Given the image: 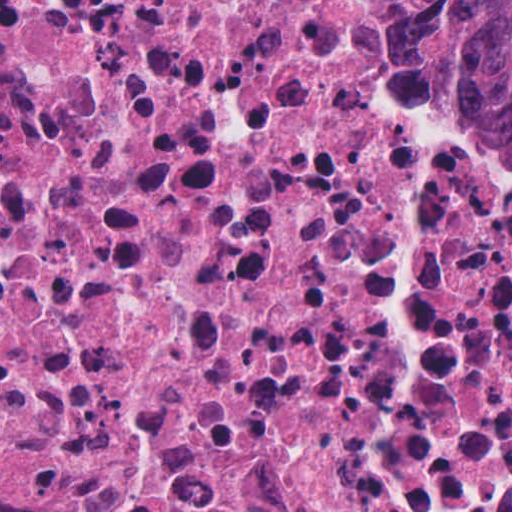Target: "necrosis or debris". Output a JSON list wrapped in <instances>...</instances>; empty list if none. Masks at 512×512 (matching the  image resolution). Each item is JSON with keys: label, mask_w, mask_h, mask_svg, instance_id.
Returning a JSON list of instances; mask_svg holds the SVG:
<instances>
[{"label": "necrosis or debris", "mask_w": 512, "mask_h": 512, "mask_svg": "<svg viewBox=\"0 0 512 512\" xmlns=\"http://www.w3.org/2000/svg\"><path fill=\"white\" fill-rule=\"evenodd\" d=\"M389 0H0V512H512V159Z\"/></svg>", "instance_id": "necrosis-or-debris-1"}]
</instances>
